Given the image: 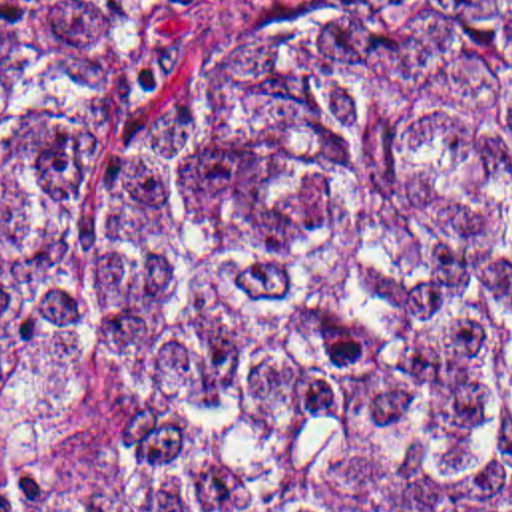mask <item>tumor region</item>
I'll use <instances>...</instances> for the list:
<instances>
[{"instance_id": "tumor-region-1", "label": "tumor region", "mask_w": 512, "mask_h": 512, "mask_svg": "<svg viewBox=\"0 0 512 512\" xmlns=\"http://www.w3.org/2000/svg\"><path fill=\"white\" fill-rule=\"evenodd\" d=\"M144 412L0 512H512V0H0V396Z\"/></svg>"}]
</instances>
